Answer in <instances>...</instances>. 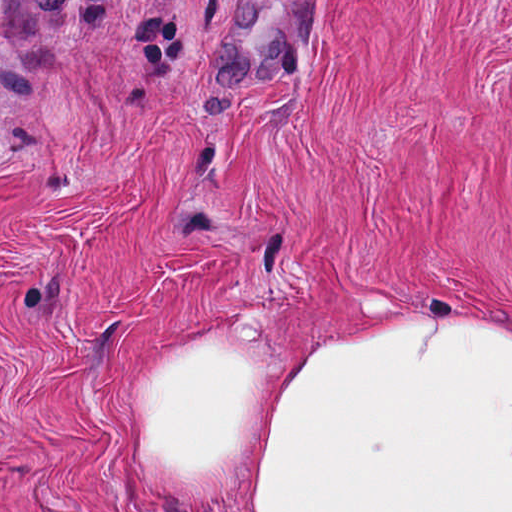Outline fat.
<instances>
[{"label":"fat","instance_id":"obj_1","mask_svg":"<svg viewBox=\"0 0 512 512\" xmlns=\"http://www.w3.org/2000/svg\"><path fill=\"white\" fill-rule=\"evenodd\" d=\"M479 317L366 323L298 362L171 333L128 384V459L175 512H512V338Z\"/></svg>","mask_w":512,"mask_h":512}]
</instances>
